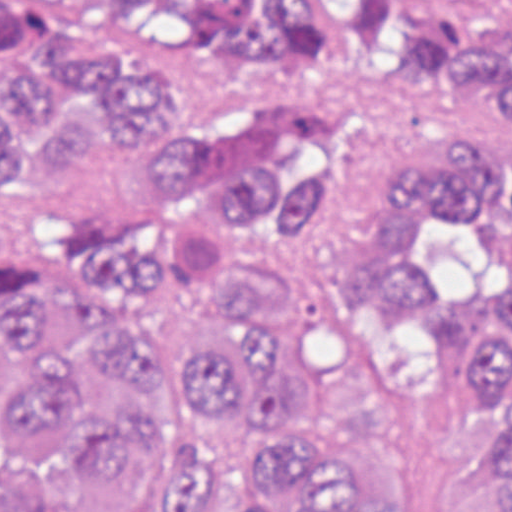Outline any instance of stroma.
Listing matches in <instances>:
<instances>
[{
	"mask_svg": "<svg viewBox=\"0 0 512 512\" xmlns=\"http://www.w3.org/2000/svg\"><path fill=\"white\" fill-rule=\"evenodd\" d=\"M0 1H512V0H0ZM202 108L218 168L245 179L287 137L342 141L347 174L310 223L304 250L256 287L251 320L271 341H303V314L338 303L326 332L337 356L314 414L286 428L244 396L223 418L194 411L175 385H142L87 358L77 330L54 316L35 336L45 362H73L109 412H144L197 440L186 464L194 512H230L271 438L332 443L346 471L375 482L385 512H454L498 466L492 412L417 283H379L390 256L395 171L411 147H491L498 140L373 53H351L314 77H199L143 108L114 162L80 198L39 207L0 265H45L72 250L77 223H132L153 243L190 303H218L272 275L281 251L223 196L195 202L142 169L147 114ZM488 141V142H487ZM82 420L67 444L38 455L12 444L0 419V512H167L185 450L157 444L110 487L77 472Z\"/></svg>",
	"mask_w": 512,
	"mask_h": 512,
	"instance_id": "1",
	"label": "stroma"
}]
</instances>
